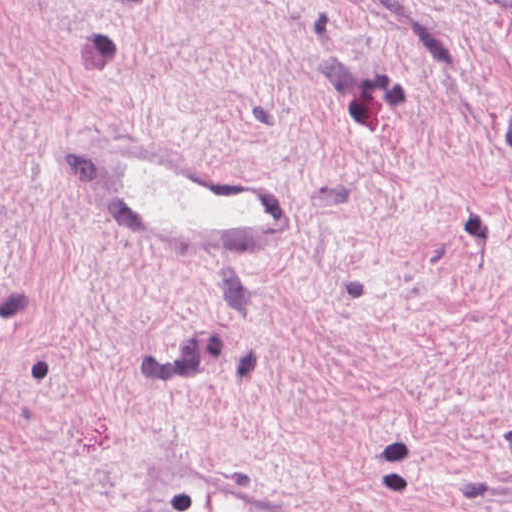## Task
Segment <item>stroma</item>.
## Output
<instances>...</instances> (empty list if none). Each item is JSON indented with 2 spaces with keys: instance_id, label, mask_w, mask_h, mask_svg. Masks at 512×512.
<instances>
[{
  "instance_id": "35a3bbf8",
  "label": "stroma",
  "mask_w": 512,
  "mask_h": 512,
  "mask_svg": "<svg viewBox=\"0 0 512 512\" xmlns=\"http://www.w3.org/2000/svg\"><path fill=\"white\" fill-rule=\"evenodd\" d=\"M126 131L286 258L130 255ZM0 512H512V0H0Z\"/></svg>"
}]
</instances>
